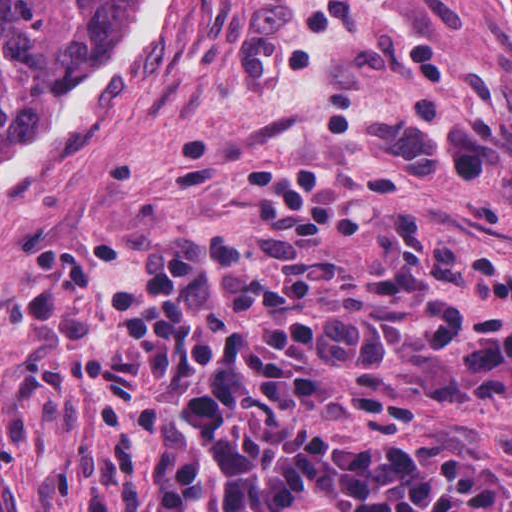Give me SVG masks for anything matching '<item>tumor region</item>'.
Here are the masks:
<instances>
[{
  "instance_id": "obj_1",
  "label": "tumor region",
  "mask_w": 512,
  "mask_h": 512,
  "mask_svg": "<svg viewBox=\"0 0 512 512\" xmlns=\"http://www.w3.org/2000/svg\"><path fill=\"white\" fill-rule=\"evenodd\" d=\"M122 2L0 0V138L98 69Z\"/></svg>"
}]
</instances>
